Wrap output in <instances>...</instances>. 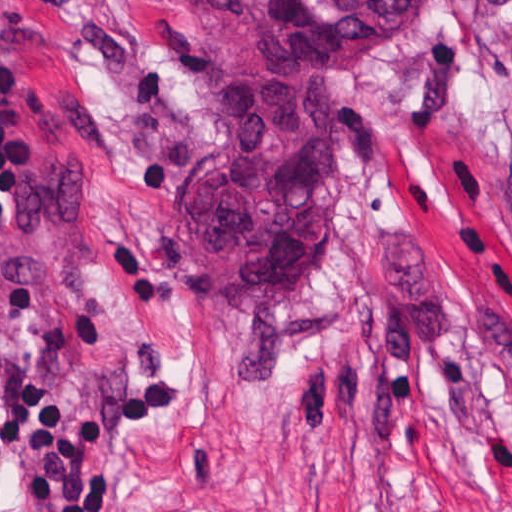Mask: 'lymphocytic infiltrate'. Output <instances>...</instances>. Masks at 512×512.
<instances>
[{
  "label": "lymphocytic infiltrate",
  "mask_w": 512,
  "mask_h": 512,
  "mask_svg": "<svg viewBox=\"0 0 512 512\" xmlns=\"http://www.w3.org/2000/svg\"><path fill=\"white\" fill-rule=\"evenodd\" d=\"M16 91L14 65L0 56V124ZM24 171L0 132V232L19 225L11 195ZM175 410V386L159 379L98 394L61 396L49 381L32 382L0 358V455L24 486L28 512H109L118 485L100 464L143 443ZM0 512H20L0 472Z\"/></svg>",
  "instance_id": "f902f5d3"
}]
</instances>
